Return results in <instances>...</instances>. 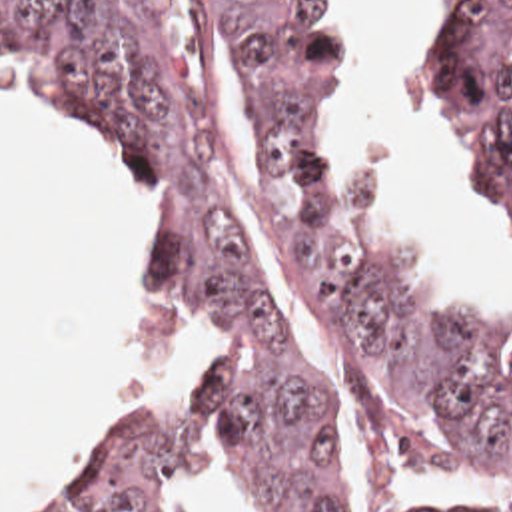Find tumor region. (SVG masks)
I'll return each mask as SVG.
<instances>
[{
	"label": "tumor region",
	"instance_id": "tumor-region-1",
	"mask_svg": "<svg viewBox=\"0 0 512 512\" xmlns=\"http://www.w3.org/2000/svg\"><path fill=\"white\" fill-rule=\"evenodd\" d=\"M192 65L138 0H0V69L110 127L154 187V307L226 311L212 377L168 424L120 430L56 512H194L216 422L241 424L281 512H349L311 389L240 243V171L216 109L218 37L269 143L277 259L345 424L353 512H512L409 500L413 474L512 468V365L413 291L365 229L345 167V0H186ZM512 0H449L405 43V103L473 169L512 255Z\"/></svg>",
	"mask_w": 512,
	"mask_h": 512
}]
</instances>
